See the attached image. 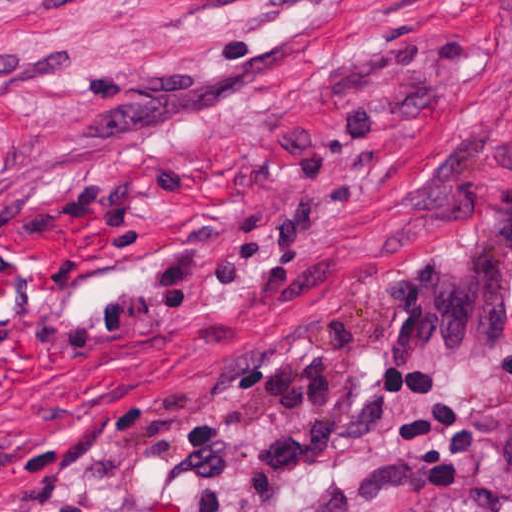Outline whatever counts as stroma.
Instances as JSON below:
<instances>
[{
    "label": "stroma",
    "instance_id": "stroma-1",
    "mask_svg": "<svg viewBox=\"0 0 512 512\" xmlns=\"http://www.w3.org/2000/svg\"><path fill=\"white\" fill-rule=\"evenodd\" d=\"M382 99L357 210L269 263L284 291L220 286L170 324L59 358L28 339L137 276L195 211H266L322 117ZM316 137L314 138V141ZM512 181V0H0V512H162L156 474L230 366L330 308L365 377L312 512H434L512 471L480 421L509 411L512 325L489 350L407 362L374 285L420 226L465 230ZM439 377L477 430L444 492L406 472L390 381Z\"/></svg>",
    "mask_w": 512,
    "mask_h": 512
}]
</instances>
